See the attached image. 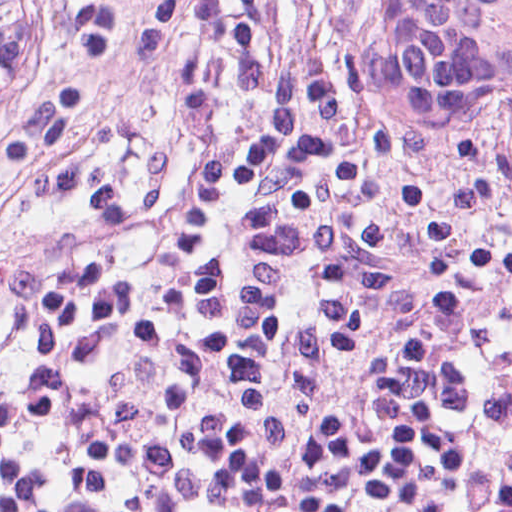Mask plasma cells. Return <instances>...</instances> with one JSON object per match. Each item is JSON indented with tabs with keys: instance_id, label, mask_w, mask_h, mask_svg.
I'll return each instance as SVG.
<instances>
[{
	"instance_id": "1",
	"label": "plasma cells",
	"mask_w": 512,
	"mask_h": 512,
	"mask_svg": "<svg viewBox=\"0 0 512 512\" xmlns=\"http://www.w3.org/2000/svg\"><path fill=\"white\" fill-rule=\"evenodd\" d=\"M257 0H43L0 198L165 206L248 100ZM0 512H512V215L230 164L140 249L0 313Z\"/></svg>"
}]
</instances>
